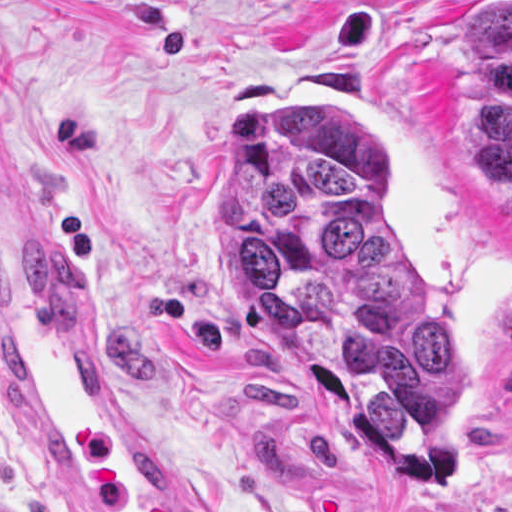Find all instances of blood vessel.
<instances>
[{"mask_svg":"<svg viewBox=\"0 0 512 512\" xmlns=\"http://www.w3.org/2000/svg\"><path fill=\"white\" fill-rule=\"evenodd\" d=\"M0 360L68 512H222L126 387L30 213L1 189Z\"/></svg>","mask_w":512,"mask_h":512,"instance_id":"obj_1","label":"blood vessel"}]
</instances>
